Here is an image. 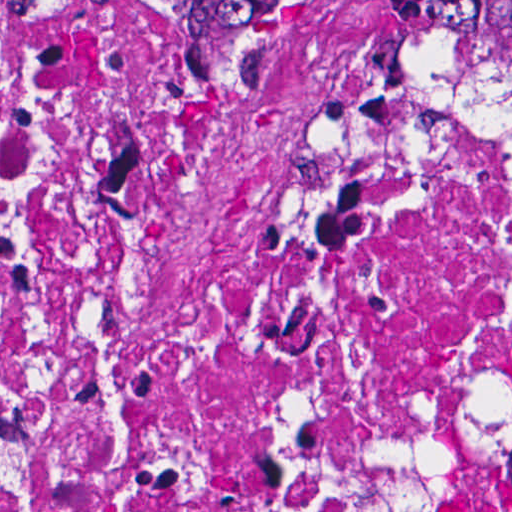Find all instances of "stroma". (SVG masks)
<instances>
[{
    "label": "stroma",
    "mask_w": 512,
    "mask_h": 512,
    "mask_svg": "<svg viewBox=\"0 0 512 512\" xmlns=\"http://www.w3.org/2000/svg\"><path fill=\"white\" fill-rule=\"evenodd\" d=\"M1 1H388L411 21L407 8L461 61L512 99L464 50L444 23L432 1L512 0H0V512H1Z\"/></svg>",
    "instance_id": "1"
}]
</instances>
